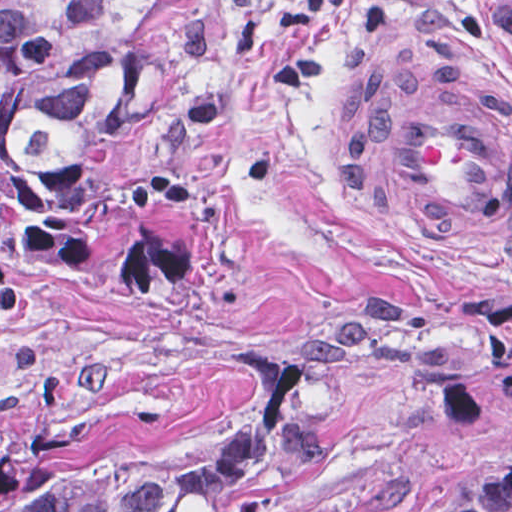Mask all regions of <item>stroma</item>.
Returning a JSON list of instances; mask_svg holds the SVG:
<instances>
[{
  "instance_id": "obj_1",
  "label": "stroma",
  "mask_w": 512,
  "mask_h": 512,
  "mask_svg": "<svg viewBox=\"0 0 512 512\" xmlns=\"http://www.w3.org/2000/svg\"><path fill=\"white\" fill-rule=\"evenodd\" d=\"M451 59L512 112V0H213L124 132L1 169L0 0V491L191 458L339 344L426 380L248 512H512V257H411L347 151L357 93Z\"/></svg>"
}]
</instances>
